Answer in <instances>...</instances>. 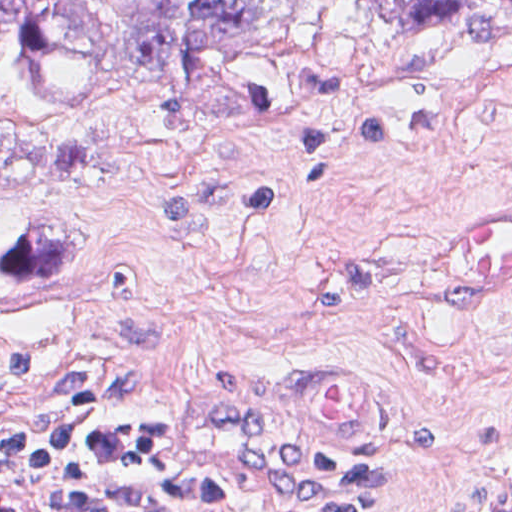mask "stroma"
<instances>
[{
	"mask_svg": "<svg viewBox=\"0 0 512 512\" xmlns=\"http://www.w3.org/2000/svg\"><path fill=\"white\" fill-rule=\"evenodd\" d=\"M304 95L234 143L168 137L165 97L62 117L105 165L1 198L0 512H56L1 467V429L63 393L169 420L214 474L288 512L332 491L307 456L383 485L371 512H490L512 485V293H458L438 231L512 205V25L398 35L311 0Z\"/></svg>",
	"mask_w": 512,
	"mask_h": 512,
	"instance_id": "stroma-1",
	"label": "stroma"
}]
</instances>
